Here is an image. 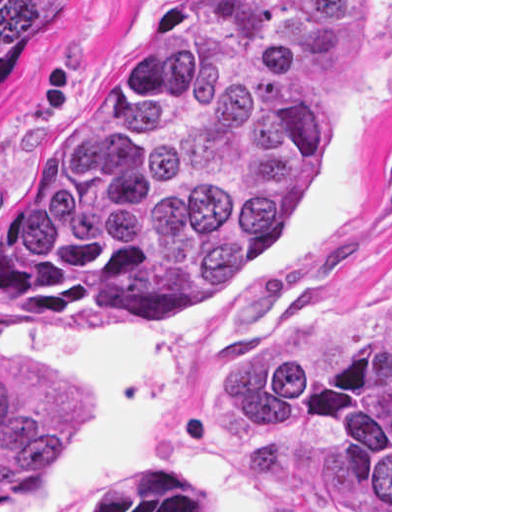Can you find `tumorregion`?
<instances>
[{"label":"tumor region","instance_id":"1","mask_svg":"<svg viewBox=\"0 0 512 512\" xmlns=\"http://www.w3.org/2000/svg\"><path fill=\"white\" fill-rule=\"evenodd\" d=\"M54 1L0 0V82ZM369 57L370 0H178L0 184L1 294L47 312L224 299L322 165L316 98ZM86 427L75 382L0 363V510ZM213 427L298 501L390 512V302L300 313L237 363Z\"/></svg>","mask_w":512,"mask_h":512}]
</instances>
